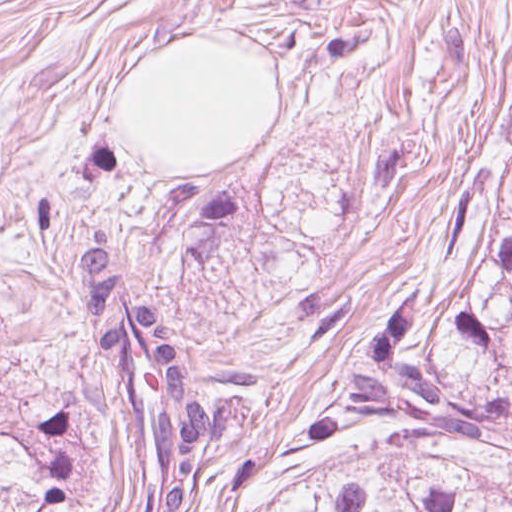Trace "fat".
Segmentation results:
<instances>
[{"mask_svg": "<svg viewBox=\"0 0 512 512\" xmlns=\"http://www.w3.org/2000/svg\"><path fill=\"white\" fill-rule=\"evenodd\" d=\"M117 120L162 169H206L275 131V77L260 48L174 36L133 61Z\"/></svg>", "mask_w": 512, "mask_h": 512, "instance_id": "fat-1", "label": "fat"}]
</instances>
